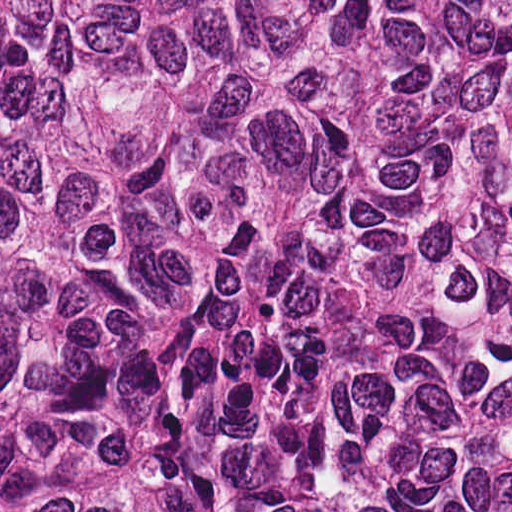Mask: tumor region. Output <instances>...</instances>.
I'll list each match as a JSON object with an SVG mask.
<instances>
[{
    "mask_svg": "<svg viewBox=\"0 0 512 512\" xmlns=\"http://www.w3.org/2000/svg\"><path fill=\"white\" fill-rule=\"evenodd\" d=\"M0 512H512V0H0Z\"/></svg>",
    "mask_w": 512,
    "mask_h": 512,
    "instance_id": "e687c5a6",
    "label": "tumor region"
}]
</instances>
